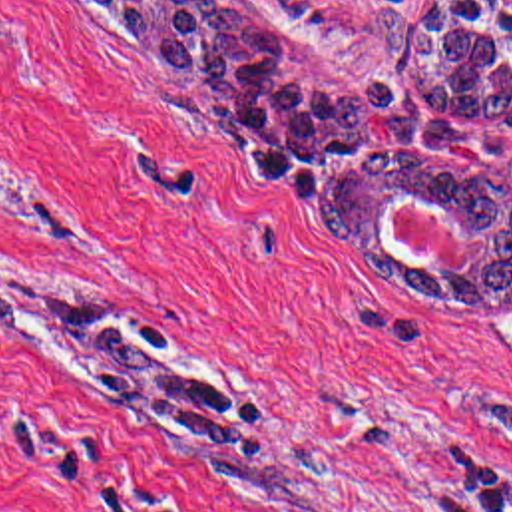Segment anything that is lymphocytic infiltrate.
<instances>
[{"instance_id":"1","label":"lymphocytic infiltrate","mask_w":512,"mask_h":512,"mask_svg":"<svg viewBox=\"0 0 512 512\" xmlns=\"http://www.w3.org/2000/svg\"><path fill=\"white\" fill-rule=\"evenodd\" d=\"M457 512H512V479H495L465 497Z\"/></svg>"}]
</instances>
